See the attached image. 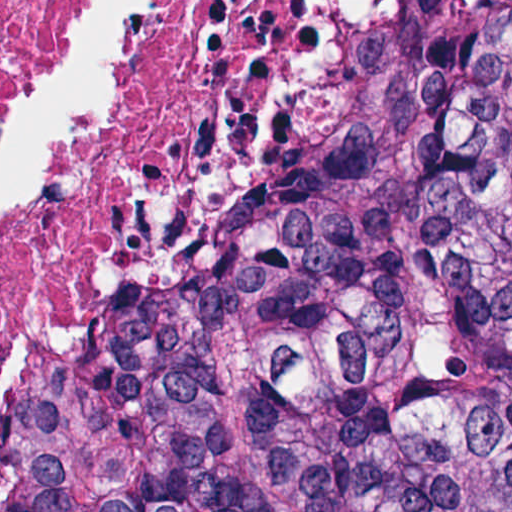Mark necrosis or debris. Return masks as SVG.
<instances>
[{"label":"necrosis or debris","instance_id":"obj_1","mask_svg":"<svg viewBox=\"0 0 512 512\" xmlns=\"http://www.w3.org/2000/svg\"><path fill=\"white\" fill-rule=\"evenodd\" d=\"M429 0H0V512H105L161 340Z\"/></svg>","mask_w":512,"mask_h":512}]
</instances>
